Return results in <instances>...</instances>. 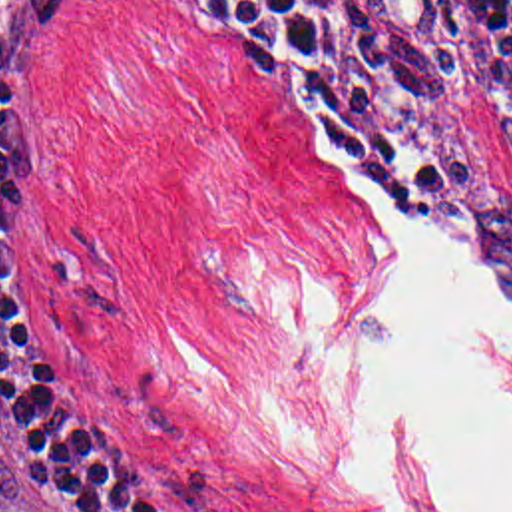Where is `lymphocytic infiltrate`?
Returning <instances> with one entry per match:
<instances>
[{
	"mask_svg": "<svg viewBox=\"0 0 512 512\" xmlns=\"http://www.w3.org/2000/svg\"><path fill=\"white\" fill-rule=\"evenodd\" d=\"M61 0L0 3V448L61 512H198L154 446L59 396L19 336L3 280V181L21 125V69ZM228 51L374 213L429 205L387 145L338 0H147ZM479 41H511L512 0H445Z\"/></svg>",
	"mask_w": 512,
	"mask_h": 512,
	"instance_id": "lymphocytic-infiltrate-1",
	"label": "lymphocytic infiltrate"
}]
</instances>
